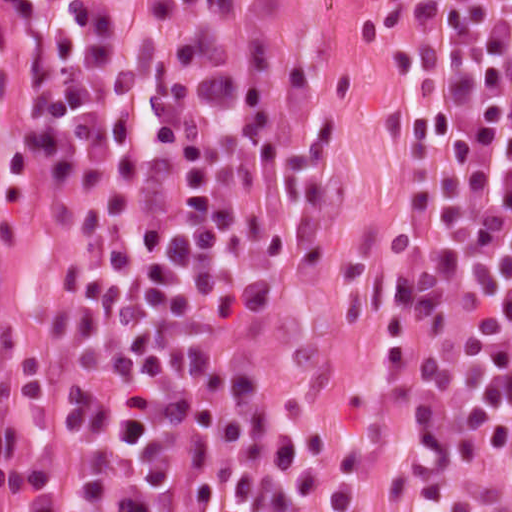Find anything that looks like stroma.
I'll return each instance as SVG.
<instances>
[{"label": "stroma", "instance_id": "obj_1", "mask_svg": "<svg viewBox=\"0 0 512 512\" xmlns=\"http://www.w3.org/2000/svg\"><path fill=\"white\" fill-rule=\"evenodd\" d=\"M112 47L234 67L293 181V236L236 303L234 343L277 431L276 483L242 512H512V463L474 492H421L384 453L408 104L474 52L504 51L512 84V0H0V336L73 257L65 223L31 220L22 87L44 60Z\"/></svg>", "mask_w": 512, "mask_h": 512}]
</instances>
